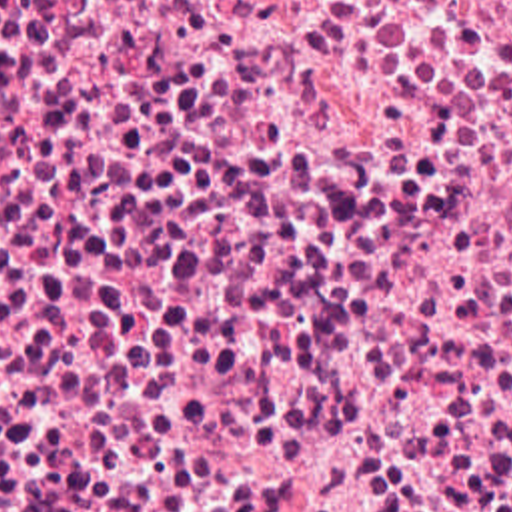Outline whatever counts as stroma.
Instances as JSON below:
<instances>
[{"label":"stroma","mask_w":512,"mask_h":512,"mask_svg":"<svg viewBox=\"0 0 512 512\" xmlns=\"http://www.w3.org/2000/svg\"><path fill=\"white\" fill-rule=\"evenodd\" d=\"M0 512H512V428H0Z\"/></svg>","instance_id":"35a3bbf8"}]
</instances>
